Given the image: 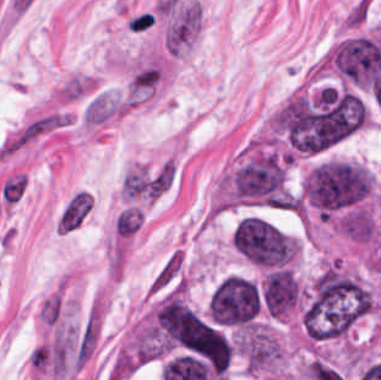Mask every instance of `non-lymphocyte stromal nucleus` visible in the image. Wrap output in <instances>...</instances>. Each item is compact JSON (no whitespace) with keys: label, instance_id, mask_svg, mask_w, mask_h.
<instances>
[{"label":"non-lymphocyte stromal nucleus","instance_id":"1","mask_svg":"<svg viewBox=\"0 0 381 380\" xmlns=\"http://www.w3.org/2000/svg\"><path fill=\"white\" fill-rule=\"evenodd\" d=\"M185 285L187 280L183 249L176 247L162 259L146 292L153 296Z\"/></svg>","mask_w":381,"mask_h":380}]
</instances>
